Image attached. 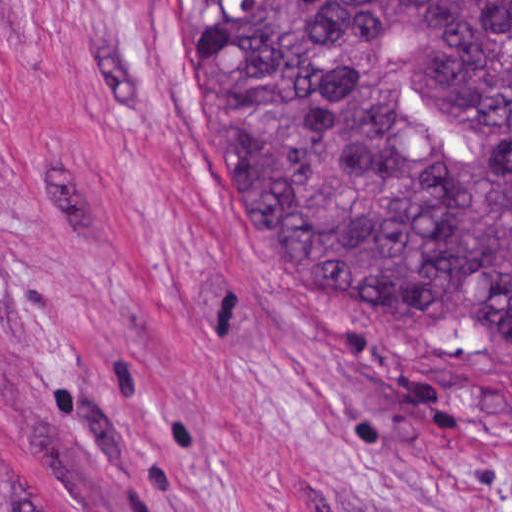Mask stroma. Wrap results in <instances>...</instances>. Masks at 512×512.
<instances>
[{"instance_id":"stroma-1","label":"stroma","mask_w":512,"mask_h":512,"mask_svg":"<svg viewBox=\"0 0 512 512\" xmlns=\"http://www.w3.org/2000/svg\"><path fill=\"white\" fill-rule=\"evenodd\" d=\"M0 454L45 512H512V351L269 253L190 0H0Z\"/></svg>"}]
</instances>
